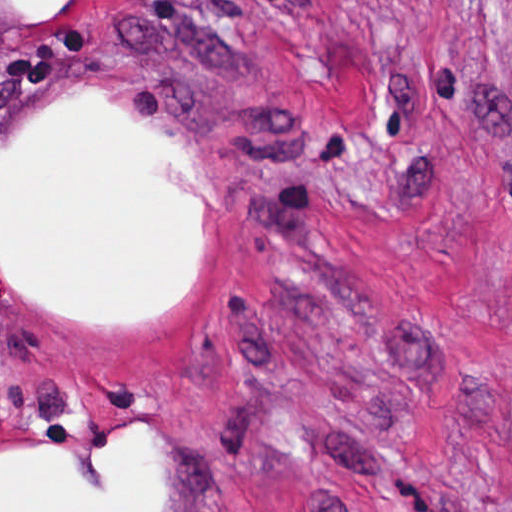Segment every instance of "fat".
Listing matches in <instances>:
<instances>
[{
  "instance_id": "fat-1",
  "label": "fat",
  "mask_w": 512,
  "mask_h": 512,
  "mask_svg": "<svg viewBox=\"0 0 512 512\" xmlns=\"http://www.w3.org/2000/svg\"><path fill=\"white\" fill-rule=\"evenodd\" d=\"M13 1L23 16L74 9V0ZM52 109L1 178V269L31 299L89 318L151 317L187 280L200 225V204L157 181L152 167L196 171L100 101ZM106 446L115 476L105 491L90 489L78 467L51 451L1 450V512H147L139 436L111 432Z\"/></svg>"
}]
</instances>
